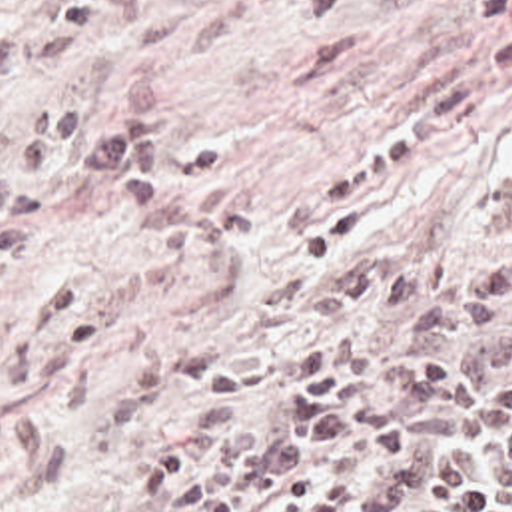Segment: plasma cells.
Segmentation results:
<instances>
[{"label": "plasma cells", "instance_id": "9512152a", "mask_svg": "<svg viewBox=\"0 0 512 512\" xmlns=\"http://www.w3.org/2000/svg\"><path fill=\"white\" fill-rule=\"evenodd\" d=\"M145 0H31L0 25V273L27 249L47 205L49 163L113 183L143 209L169 189L171 157L155 85L131 65L111 99L65 109L63 67L135 23ZM512 91V19L437 81L393 135L339 177L303 193L277 223L303 237L365 191L403 175ZM503 203L512 217V163ZM305 313L339 329L205 386L265 406L283 372L297 384L277 428L239 426L209 474L185 452L149 458L141 492L163 512H512V229L467 265L453 249L397 267L365 253L313 291Z\"/></svg>", "mask_w": 512, "mask_h": 512}]
</instances>
